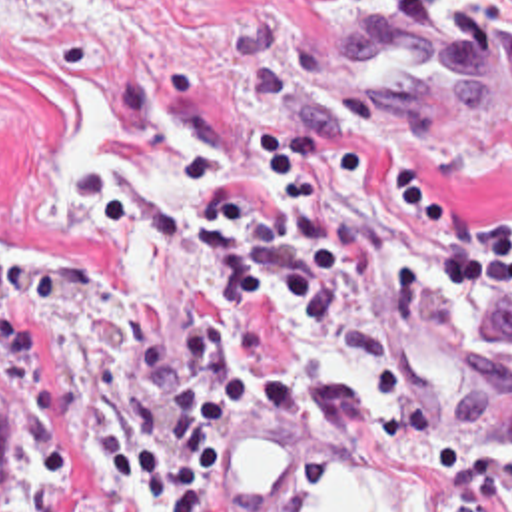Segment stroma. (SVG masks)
Returning <instances> with one entry per match:
<instances>
[{
	"instance_id": "1",
	"label": "stroma",
	"mask_w": 512,
	"mask_h": 512,
	"mask_svg": "<svg viewBox=\"0 0 512 512\" xmlns=\"http://www.w3.org/2000/svg\"><path fill=\"white\" fill-rule=\"evenodd\" d=\"M368 13L512 49V0H0V386L13 400L0 512H163L125 486L87 406L111 402L159 444L169 398L139 375L135 333L173 355L187 315L217 313L237 317L243 353L277 359L301 390L291 416L231 426L223 512H301L340 462L382 464L426 486L442 512L426 460L370 426V410L392 402L428 410L492 486L512 452V299L438 287L426 251L382 239L366 189H340L334 203L358 213L380 273L414 253L422 307L402 337L372 331L360 293L317 331L277 307H217L207 261L159 243V211L201 209L179 179V153H207L265 193L247 143L279 125L370 139L384 163L420 167L428 195L472 221L512 219V123L382 101L346 47ZM63 83L117 121L159 171L157 191L109 213L85 191L57 219L41 215V191L67 155ZM257 442L293 452V474L271 502L239 496V462Z\"/></svg>"
}]
</instances>
